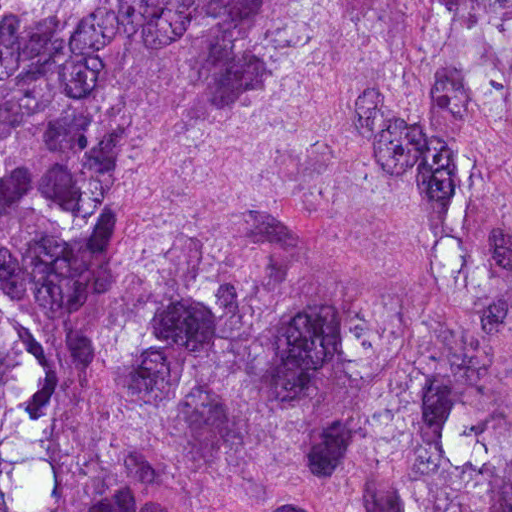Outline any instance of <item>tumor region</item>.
<instances>
[{"mask_svg":"<svg viewBox=\"0 0 512 512\" xmlns=\"http://www.w3.org/2000/svg\"><path fill=\"white\" fill-rule=\"evenodd\" d=\"M0 512H512V0H0Z\"/></svg>","mask_w":512,"mask_h":512,"instance_id":"obj_1","label":"tumor region"}]
</instances>
